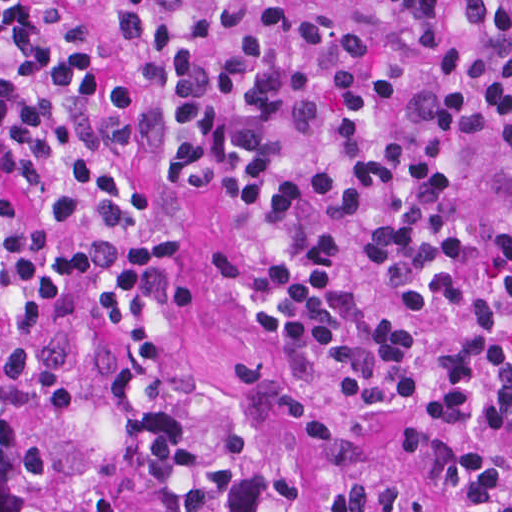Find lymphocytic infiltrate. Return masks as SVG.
Masks as SVG:
<instances>
[{
  "mask_svg": "<svg viewBox=\"0 0 512 512\" xmlns=\"http://www.w3.org/2000/svg\"><path fill=\"white\" fill-rule=\"evenodd\" d=\"M219 198L237 308L290 365L406 398L446 512H512V0H0V267L115 331L212 479L275 378L170 376L185 246L135 156Z\"/></svg>",
  "mask_w": 512,
  "mask_h": 512,
  "instance_id": "lymphocytic-infiltrate-1",
  "label": "lymphocytic infiltrate"
}]
</instances>
